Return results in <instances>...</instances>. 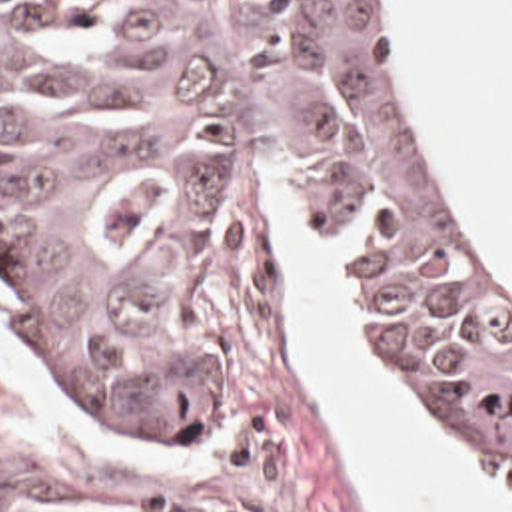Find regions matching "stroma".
Segmentation results:
<instances>
[{"mask_svg": "<svg viewBox=\"0 0 512 512\" xmlns=\"http://www.w3.org/2000/svg\"><path fill=\"white\" fill-rule=\"evenodd\" d=\"M25 1L127 47H195L219 33L239 0ZM381 5L418 133L472 239L512 277V243L474 199L454 155L434 135L391 25L389 0ZM261 163L269 191L297 223L343 251L337 299L383 389L494 492L512 500V478L502 464L450 423L391 357L359 243L323 219L303 185L257 147L239 151L235 229L209 269L199 303V333L219 379V440L139 444L85 405L47 361L41 331L0 263V303L15 341L53 381L71 417L143 454L173 456V466H153L119 444L65 431L0 361V512H375L331 434L315 389L289 357L283 277L269 243Z\"/></svg>", "mask_w": 512, "mask_h": 512, "instance_id": "1", "label": "stroma"}]
</instances>
